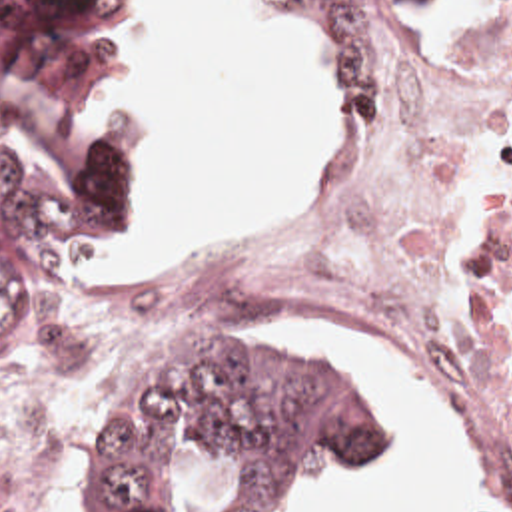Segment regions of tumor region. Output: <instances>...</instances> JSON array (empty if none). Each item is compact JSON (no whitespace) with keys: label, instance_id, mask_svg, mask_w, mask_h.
<instances>
[{"label":"tumor region","instance_id":"obj_1","mask_svg":"<svg viewBox=\"0 0 512 512\" xmlns=\"http://www.w3.org/2000/svg\"><path fill=\"white\" fill-rule=\"evenodd\" d=\"M341 27V129H367L405 81L417 21L449 0H289ZM122 0H0V115L66 169L54 185L0 151V390L20 386L46 279L132 231L144 199L114 51ZM387 404L317 326H214L124 372L84 426L76 512H154L188 464L234 454L249 512H299L311 472L367 466Z\"/></svg>","mask_w":512,"mask_h":512}]
</instances>
